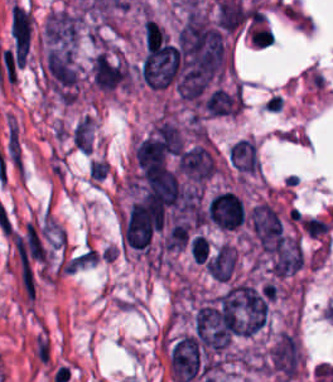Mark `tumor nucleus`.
<instances>
[{
    "mask_svg": "<svg viewBox=\"0 0 333 382\" xmlns=\"http://www.w3.org/2000/svg\"><path fill=\"white\" fill-rule=\"evenodd\" d=\"M250 228L264 252L278 253L283 231L281 222L271 206L259 204L249 211Z\"/></svg>",
    "mask_w": 333,
    "mask_h": 382,
    "instance_id": "obj_1",
    "label": "tumor nucleus"
},
{
    "mask_svg": "<svg viewBox=\"0 0 333 382\" xmlns=\"http://www.w3.org/2000/svg\"><path fill=\"white\" fill-rule=\"evenodd\" d=\"M267 364L272 373L284 379H293L300 367L297 339L290 331H283L270 346Z\"/></svg>",
    "mask_w": 333,
    "mask_h": 382,
    "instance_id": "obj_2",
    "label": "tumor nucleus"
},
{
    "mask_svg": "<svg viewBox=\"0 0 333 382\" xmlns=\"http://www.w3.org/2000/svg\"><path fill=\"white\" fill-rule=\"evenodd\" d=\"M169 362L177 382H192L199 369L198 338L182 336L172 346Z\"/></svg>",
    "mask_w": 333,
    "mask_h": 382,
    "instance_id": "obj_3",
    "label": "tumor nucleus"
},
{
    "mask_svg": "<svg viewBox=\"0 0 333 382\" xmlns=\"http://www.w3.org/2000/svg\"><path fill=\"white\" fill-rule=\"evenodd\" d=\"M206 214L221 229H235L245 216L244 205L233 191H220L207 205Z\"/></svg>",
    "mask_w": 333,
    "mask_h": 382,
    "instance_id": "obj_4",
    "label": "tumor nucleus"
},
{
    "mask_svg": "<svg viewBox=\"0 0 333 382\" xmlns=\"http://www.w3.org/2000/svg\"><path fill=\"white\" fill-rule=\"evenodd\" d=\"M234 268L235 253L226 243L206 262L208 274L219 281L226 282Z\"/></svg>",
    "mask_w": 333,
    "mask_h": 382,
    "instance_id": "obj_5",
    "label": "tumor nucleus"
},
{
    "mask_svg": "<svg viewBox=\"0 0 333 382\" xmlns=\"http://www.w3.org/2000/svg\"><path fill=\"white\" fill-rule=\"evenodd\" d=\"M232 164L240 171L252 172L259 168L255 144L245 139L232 143L229 152Z\"/></svg>",
    "mask_w": 333,
    "mask_h": 382,
    "instance_id": "obj_6",
    "label": "tumor nucleus"
},
{
    "mask_svg": "<svg viewBox=\"0 0 333 382\" xmlns=\"http://www.w3.org/2000/svg\"><path fill=\"white\" fill-rule=\"evenodd\" d=\"M72 139L81 152H91V119L87 115L76 124Z\"/></svg>",
    "mask_w": 333,
    "mask_h": 382,
    "instance_id": "obj_7",
    "label": "tumor nucleus"
}]
</instances>
